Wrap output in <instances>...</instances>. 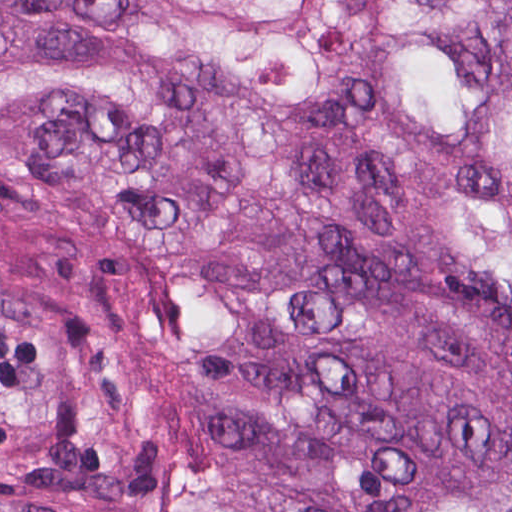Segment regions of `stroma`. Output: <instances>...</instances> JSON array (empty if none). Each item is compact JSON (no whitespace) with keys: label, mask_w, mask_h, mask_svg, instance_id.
I'll return each mask as SVG.
<instances>
[{"label":"stroma","mask_w":512,"mask_h":512,"mask_svg":"<svg viewBox=\"0 0 512 512\" xmlns=\"http://www.w3.org/2000/svg\"><path fill=\"white\" fill-rule=\"evenodd\" d=\"M361 1L371 123L390 140L446 158L483 209L512 214V195L495 184L476 145L480 128L430 133L384 107L376 65L397 35V15L377 0ZM0 305L101 361L149 447L145 469L0 479V507L183 512L178 493L186 481L218 479L291 512H360L231 445L207 300L160 226L114 206L0 187Z\"/></svg>","instance_id":"stroma-1"}]
</instances>
